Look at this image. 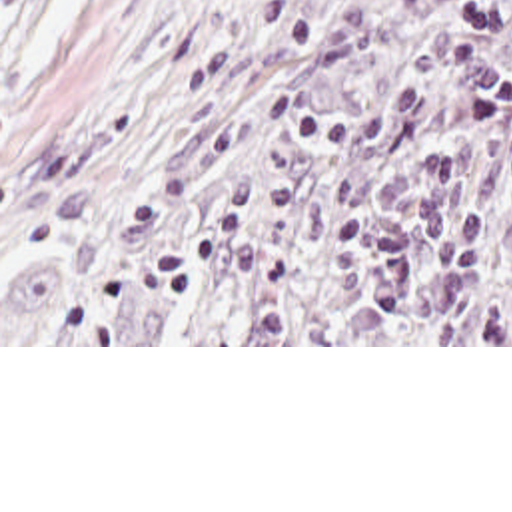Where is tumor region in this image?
Returning <instances> with one entry per match:
<instances>
[{
    "label": "tumor region",
    "mask_w": 512,
    "mask_h": 512,
    "mask_svg": "<svg viewBox=\"0 0 512 512\" xmlns=\"http://www.w3.org/2000/svg\"><path fill=\"white\" fill-rule=\"evenodd\" d=\"M2 343L512 345V0H290Z\"/></svg>",
    "instance_id": "obj_1"
}]
</instances>
